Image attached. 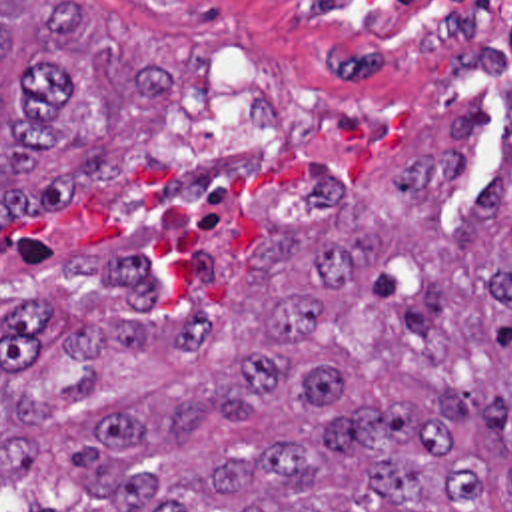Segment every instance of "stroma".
Wrapping results in <instances>:
<instances>
[{"instance_id":"35a3bbf8","label":"stroma","mask_w":512,"mask_h":512,"mask_svg":"<svg viewBox=\"0 0 512 512\" xmlns=\"http://www.w3.org/2000/svg\"><path fill=\"white\" fill-rule=\"evenodd\" d=\"M176 47V99L126 109L114 177L82 183L46 215L0 225V309L18 291L96 281L74 255L136 253L154 275H194L196 253L252 257L268 225L328 213L304 175L338 171L368 189L432 147L485 93L491 107L445 215L473 211L501 143L512 41L481 53H414L352 11L310 0H86ZM0 512H28L0 480Z\"/></svg>"}]
</instances>
